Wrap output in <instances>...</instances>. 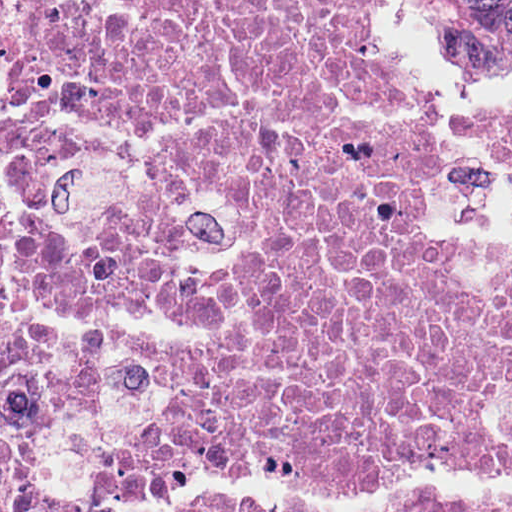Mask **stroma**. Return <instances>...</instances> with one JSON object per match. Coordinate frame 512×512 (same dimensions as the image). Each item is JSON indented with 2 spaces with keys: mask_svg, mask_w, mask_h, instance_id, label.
<instances>
[{
  "mask_svg": "<svg viewBox=\"0 0 512 512\" xmlns=\"http://www.w3.org/2000/svg\"><path fill=\"white\" fill-rule=\"evenodd\" d=\"M373 28L385 65L441 126V161L428 183V224L435 241L454 250H512V170L471 121L512 92V65L489 73L456 67L439 45L424 0H377ZM0 32L12 53L8 0H0ZM28 228L13 168L1 171L0 274Z\"/></svg>",
  "mask_w": 512,
  "mask_h": 512,
  "instance_id": "35a3bbf8",
  "label": "stroma"
}]
</instances>
